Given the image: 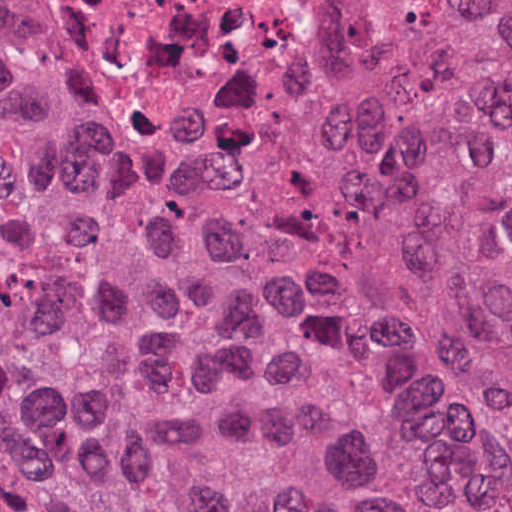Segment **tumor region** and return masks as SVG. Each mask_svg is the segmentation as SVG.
<instances>
[{"instance_id":"1","label":"tumor region","mask_w":512,"mask_h":512,"mask_svg":"<svg viewBox=\"0 0 512 512\" xmlns=\"http://www.w3.org/2000/svg\"><path fill=\"white\" fill-rule=\"evenodd\" d=\"M342 1L219 160L0 76V512H512V0Z\"/></svg>"}]
</instances>
